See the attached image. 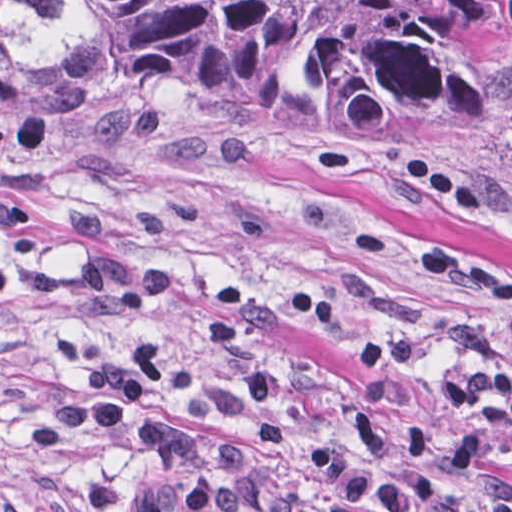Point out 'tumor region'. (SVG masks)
I'll return each mask as SVG.
<instances>
[{"mask_svg":"<svg viewBox=\"0 0 512 512\" xmlns=\"http://www.w3.org/2000/svg\"><path fill=\"white\" fill-rule=\"evenodd\" d=\"M512 0H0V110L190 107L308 152L512 138Z\"/></svg>","mask_w":512,"mask_h":512,"instance_id":"obj_1","label":"tumor region"}]
</instances>
